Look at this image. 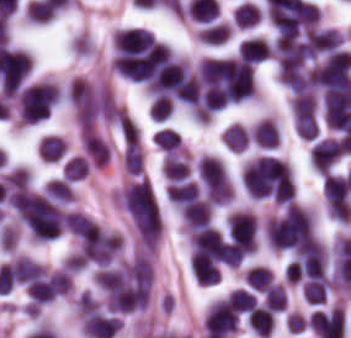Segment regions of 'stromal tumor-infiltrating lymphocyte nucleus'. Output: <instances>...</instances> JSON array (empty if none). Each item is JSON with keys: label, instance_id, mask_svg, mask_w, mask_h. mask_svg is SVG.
Returning a JSON list of instances; mask_svg holds the SVG:
<instances>
[{"label": "stromal tumor-infiltrating lymphocyte nucleus", "instance_id": "18", "mask_svg": "<svg viewBox=\"0 0 351 338\" xmlns=\"http://www.w3.org/2000/svg\"><path fill=\"white\" fill-rule=\"evenodd\" d=\"M227 299L236 311L249 312L257 305L251 291L241 286L231 290L227 294Z\"/></svg>", "mask_w": 351, "mask_h": 338}, {"label": "stromal tumor-infiltrating lymphocyte nucleus", "instance_id": "3", "mask_svg": "<svg viewBox=\"0 0 351 338\" xmlns=\"http://www.w3.org/2000/svg\"><path fill=\"white\" fill-rule=\"evenodd\" d=\"M42 264L27 255H14L0 263V275L19 282L41 277Z\"/></svg>", "mask_w": 351, "mask_h": 338}, {"label": "stromal tumor-infiltrating lymphocyte nucleus", "instance_id": "8", "mask_svg": "<svg viewBox=\"0 0 351 338\" xmlns=\"http://www.w3.org/2000/svg\"><path fill=\"white\" fill-rule=\"evenodd\" d=\"M232 30L225 20L209 22L196 31V36L201 43L217 45L231 34Z\"/></svg>", "mask_w": 351, "mask_h": 338}, {"label": "stromal tumor-infiltrating lymphocyte nucleus", "instance_id": "20", "mask_svg": "<svg viewBox=\"0 0 351 338\" xmlns=\"http://www.w3.org/2000/svg\"><path fill=\"white\" fill-rule=\"evenodd\" d=\"M173 108L168 96L156 94L148 107V117L154 121H163L171 114Z\"/></svg>", "mask_w": 351, "mask_h": 338}, {"label": "stromal tumor-infiltrating lymphocyte nucleus", "instance_id": "15", "mask_svg": "<svg viewBox=\"0 0 351 338\" xmlns=\"http://www.w3.org/2000/svg\"><path fill=\"white\" fill-rule=\"evenodd\" d=\"M262 10L250 1H243L237 5L232 18L237 27H250L260 19Z\"/></svg>", "mask_w": 351, "mask_h": 338}, {"label": "stromal tumor-infiltrating lymphocyte nucleus", "instance_id": "1", "mask_svg": "<svg viewBox=\"0 0 351 338\" xmlns=\"http://www.w3.org/2000/svg\"><path fill=\"white\" fill-rule=\"evenodd\" d=\"M228 238L241 249H257L258 218L253 211L236 209L226 219Z\"/></svg>", "mask_w": 351, "mask_h": 338}, {"label": "stromal tumor-infiltrating lymphocyte nucleus", "instance_id": "14", "mask_svg": "<svg viewBox=\"0 0 351 338\" xmlns=\"http://www.w3.org/2000/svg\"><path fill=\"white\" fill-rule=\"evenodd\" d=\"M228 149L240 151L250 140V132L239 122H232L221 134Z\"/></svg>", "mask_w": 351, "mask_h": 338}, {"label": "stromal tumor-infiltrating lymphocyte nucleus", "instance_id": "4", "mask_svg": "<svg viewBox=\"0 0 351 338\" xmlns=\"http://www.w3.org/2000/svg\"><path fill=\"white\" fill-rule=\"evenodd\" d=\"M184 227L190 234L210 224L212 205L204 199H196L180 210Z\"/></svg>", "mask_w": 351, "mask_h": 338}, {"label": "stromal tumor-infiltrating lymphocyte nucleus", "instance_id": "10", "mask_svg": "<svg viewBox=\"0 0 351 338\" xmlns=\"http://www.w3.org/2000/svg\"><path fill=\"white\" fill-rule=\"evenodd\" d=\"M67 150L64 137L46 134L38 143V153L45 161H55Z\"/></svg>", "mask_w": 351, "mask_h": 338}, {"label": "stromal tumor-infiltrating lymphocyte nucleus", "instance_id": "11", "mask_svg": "<svg viewBox=\"0 0 351 338\" xmlns=\"http://www.w3.org/2000/svg\"><path fill=\"white\" fill-rule=\"evenodd\" d=\"M43 195L58 202H71L75 200V193L70 182L60 176H53L48 180Z\"/></svg>", "mask_w": 351, "mask_h": 338}, {"label": "stromal tumor-infiltrating lymphocyte nucleus", "instance_id": "17", "mask_svg": "<svg viewBox=\"0 0 351 338\" xmlns=\"http://www.w3.org/2000/svg\"><path fill=\"white\" fill-rule=\"evenodd\" d=\"M265 308L278 312L285 309V292L281 283L272 282L263 293Z\"/></svg>", "mask_w": 351, "mask_h": 338}, {"label": "stromal tumor-infiltrating lymphocyte nucleus", "instance_id": "12", "mask_svg": "<svg viewBox=\"0 0 351 338\" xmlns=\"http://www.w3.org/2000/svg\"><path fill=\"white\" fill-rule=\"evenodd\" d=\"M162 172L166 180H178L190 173L189 163L175 151L164 155Z\"/></svg>", "mask_w": 351, "mask_h": 338}, {"label": "stromal tumor-infiltrating lymphocyte nucleus", "instance_id": "7", "mask_svg": "<svg viewBox=\"0 0 351 338\" xmlns=\"http://www.w3.org/2000/svg\"><path fill=\"white\" fill-rule=\"evenodd\" d=\"M238 58L252 63H259L270 58L269 41L263 37H249L238 46Z\"/></svg>", "mask_w": 351, "mask_h": 338}, {"label": "stromal tumor-infiltrating lymphocyte nucleus", "instance_id": "6", "mask_svg": "<svg viewBox=\"0 0 351 338\" xmlns=\"http://www.w3.org/2000/svg\"><path fill=\"white\" fill-rule=\"evenodd\" d=\"M251 139L259 147L271 148L280 143V129L274 117H261L254 122Z\"/></svg>", "mask_w": 351, "mask_h": 338}, {"label": "stromal tumor-infiltrating lymphocyte nucleus", "instance_id": "5", "mask_svg": "<svg viewBox=\"0 0 351 338\" xmlns=\"http://www.w3.org/2000/svg\"><path fill=\"white\" fill-rule=\"evenodd\" d=\"M80 139L92 164L98 168L110 160V148L96 133L82 128Z\"/></svg>", "mask_w": 351, "mask_h": 338}, {"label": "stromal tumor-infiltrating lymphocyte nucleus", "instance_id": "2", "mask_svg": "<svg viewBox=\"0 0 351 338\" xmlns=\"http://www.w3.org/2000/svg\"><path fill=\"white\" fill-rule=\"evenodd\" d=\"M341 151V141L323 137L315 141L310 148V164L318 172L327 174L336 163Z\"/></svg>", "mask_w": 351, "mask_h": 338}, {"label": "stromal tumor-infiltrating lymphocyte nucleus", "instance_id": "13", "mask_svg": "<svg viewBox=\"0 0 351 338\" xmlns=\"http://www.w3.org/2000/svg\"><path fill=\"white\" fill-rule=\"evenodd\" d=\"M243 277L249 288L263 292L273 279V273L269 267L253 264L244 271Z\"/></svg>", "mask_w": 351, "mask_h": 338}, {"label": "stromal tumor-infiltrating lymphocyte nucleus", "instance_id": "9", "mask_svg": "<svg viewBox=\"0 0 351 338\" xmlns=\"http://www.w3.org/2000/svg\"><path fill=\"white\" fill-rule=\"evenodd\" d=\"M275 316L260 305H256L247 314V324L261 337H269L274 326Z\"/></svg>", "mask_w": 351, "mask_h": 338}, {"label": "stromal tumor-infiltrating lymphocyte nucleus", "instance_id": "19", "mask_svg": "<svg viewBox=\"0 0 351 338\" xmlns=\"http://www.w3.org/2000/svg\"><path fill=\"white\" fill-rule=\"evenodd\" d=\"M158 147L167 152H172L179 147L180 137L173 127H159L152 136Z\"/></svg>", "mask_w": 351, "mask_h": 338}, {"label": "stromal tumor-infiltrating lymphocyte nucleus", "instance_id": "16", "mask_svg": "<svg viewBox=\"0 0 351 338\" xmlns=\"http://www.w3.org/2000/svg\"><path fill=\"white\" fill-rule=\"evenodd\" d=\"M63 177L70 180L85 179L89 173V160L81 154L69 157L62 169Z\"/></svg>", "mask_w": 351, "mask_h": 338}]
</instances>
